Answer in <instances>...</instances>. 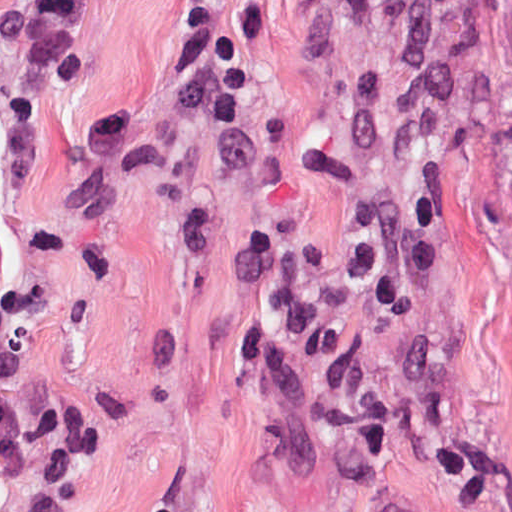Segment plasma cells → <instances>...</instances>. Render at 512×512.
Masks as SVG:
<instances>
[{
	"mask_svg": "<svg viewBox=\"0 0 512 512\" xmlns=\"http://www.w3.org/2000/svg\"><path fill=\"white\" fill-rule=\"evenodd\" d=\"M223 0H180L169 23L165 79L176 116L225 131L246 106V67L222 15ZM88 0H11L0 6V46L17 62L67 85L84 76L78 19ZM137 137V111L115 106L91 115L92 157H126ZM431 192L365 208L360 253L316 284L289 263L278 234L253 235L232 274L272 277L273 300L255 308L234 338L236 359L274 364L289 357L318 389L326 435L352 464H385L395 455L399 421L379 387L361 371L337 325L361 309L395 314L435 278L436 250L428 234ZM42 300L40 289L17 284L0 291V463L23 482L67 480L100 453V406L79 399L25 398L3 384L19 359V328ZM152 512H168L157 508Z\"/></svg>",
	"mask_w": 512,
	"mask_h": 512,
	"instance_id": "plasma-cells-1",
	"label": "plasma cells"
}]
</instances>
